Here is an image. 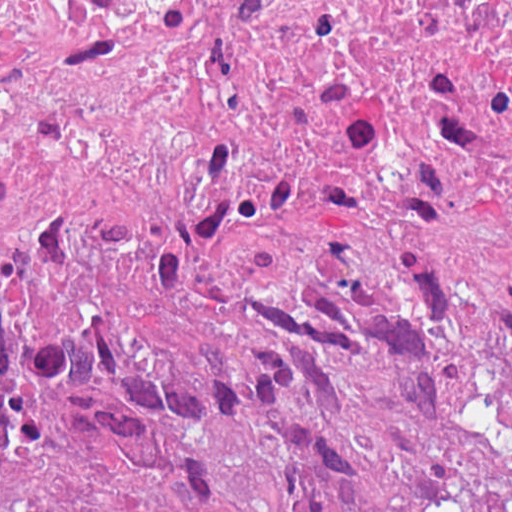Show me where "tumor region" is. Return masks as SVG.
<instances>
[{"instance_id":"tumor-region-1","label":"tumor region","mask_w":512,"mask_h":512,"mask_svg":"<svg viewBox=\"0 0 512 512\" xmlns=\"http://www.w3.org/2000/svg\"><path fill=\"white\" fill-rule=\"evenodd\" d=\"M0 233L1 512H512V120Z\"/></svg>"}]
</instances>
